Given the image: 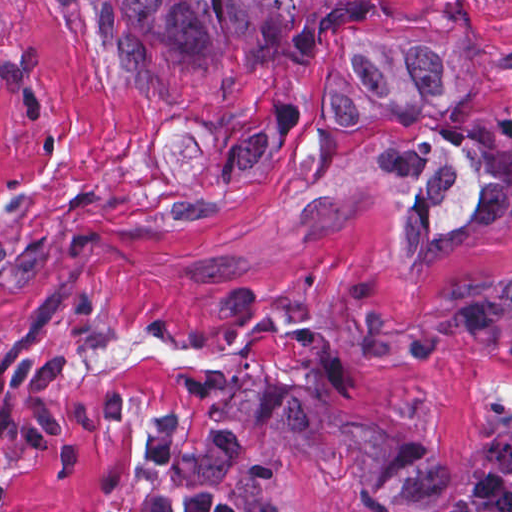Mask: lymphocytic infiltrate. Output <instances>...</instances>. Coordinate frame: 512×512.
I'll list each match as a JSON object with an SVG mask.
<instances>
[{"mask_svg": "<svg viewBox=\"0 0 512 512\" xmlns=\"http://www.w3.org/2000/svg\"><path fill=\"white\" fill-rule=\"evenodd\" d=\"M92 512H258L232 493L206 488L190 494L105 505Z\"/></svg>", "mask_w": 512, "mask_h": 512, "instance_id": "lymphocytic-infiltrate-1", "label": "lymphocytic infiltrate"}]
</instances>
